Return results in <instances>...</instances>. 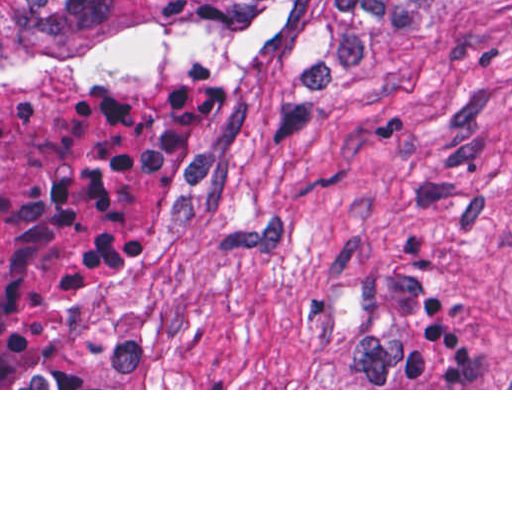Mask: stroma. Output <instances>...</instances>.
Here are the masks:
<instances>
[{"label":"stroma","instance_id":"stroma-1","mask_svg":"<svg viewBox=\"0 0 512 512\" xmlns=\"http://www.w3.org/2000/svg\"><path fill=\"white\" fill-rule=\"evenodd\" d=\"M204 83L245 114L222 205L167 218L63 352L86 388L512 390V0L403 28L392 86L295 109L193 54L0 84Z\"/></svg>","mask_w":512,"mask_h":512}]
</instances>
